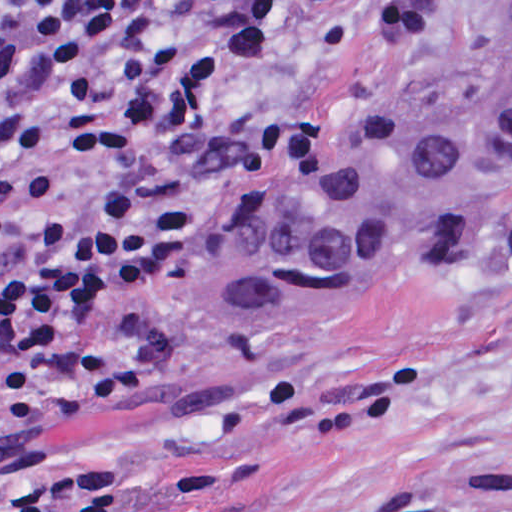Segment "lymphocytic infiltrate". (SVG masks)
<instances>
[{
  "instance_id": "f902f5d3",
  "label": "lymphocytic infiltrate",
  "mask_w": 512,
  "mask_h": 512,
  "mask_svg": "<svg viewBox=\"0 0 512 512\" xmlns=\"http://www.w3.org/2000/svg\"><path fill=\"white\" fill-rule=\"evenodd\" d=\"M348 1L0 0V431L103 304L38 480L0 512H104L55 475L47 432L122 393L125 310L324 151L345 93L309 76Z\"/></svg>"
}]
</instances>
